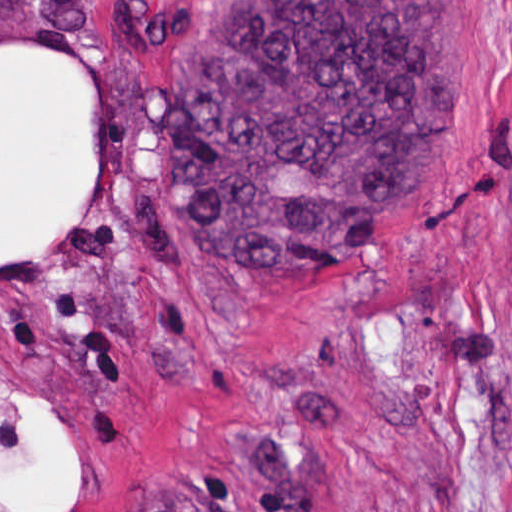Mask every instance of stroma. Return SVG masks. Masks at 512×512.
<instances>
[{
  "instance_id": "1",
  "label": "stroma",
  "mask_w": 512,
  "mask_h": 512,
  "mask_svg": "<svg viewBox=\"0 0 512 512\" xmlns=\"http://www.w3.org/2000/svg\"><path fill=\"white\" fill-rule=\"evenodd\" d=\"M199 1H462L455 135L418 203L333 269L234 265L162 178ZM99 78L81 213L1 259V45ZM40 395L74 512H512V0H0L1 460Z\"/></svg>"
}]
</instances>
